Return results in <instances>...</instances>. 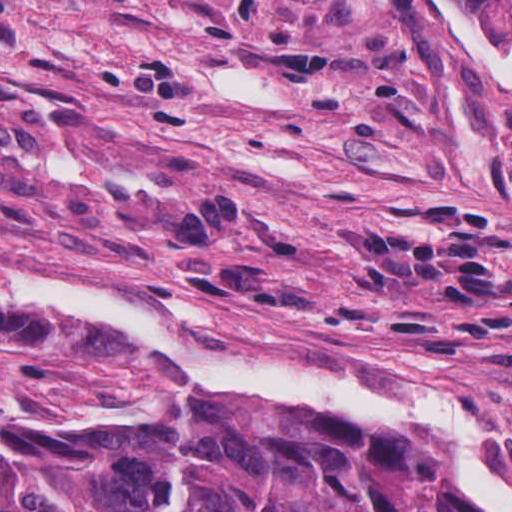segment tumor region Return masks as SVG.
Returning <instances> with one entry per match:
<instances>
[{
    "label": "tumor region",
    "mask_w": 512,
    "mask_h": 512,
    "mask_svg": "<svg viewBox=\"0 0 512 512\" xmlns=\"http://www.w3.org/2000/svg\"><path fill=\"white\" fill-rule=\"evenodd\" d=\"M512 55V0H460ZM0 512H476L417 427L223 398L151 419L0 409Z\"/></svg>",
    "instance_id": "e687c5a6"
}]
</instances>
